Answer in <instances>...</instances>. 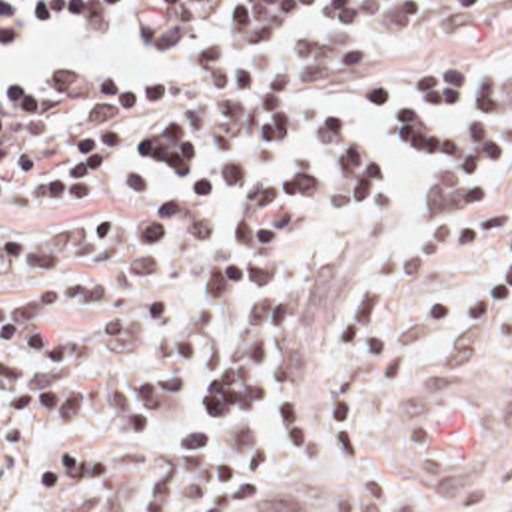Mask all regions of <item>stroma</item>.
Masks as SVG:
<instances>
[{"label": "stroma", "instance_id": "obj_1", "mask_svg": "<svg viewBox=\"0 0 512 512\" xmlns=\"http://www.w3.org/2000/svg\"><path fill=\"white\" fill-rule=\"evenodd\" d=\"M217 10L219 4L215 6L209 28L203 32H217ZM55 16L71 14L59 12ZM510 18L512 0H416V16L412 22L388 36H369L337 22L333 10V26L327 32L301 38L293 48L307 64V124L319 114H345L373 124L359 110L351 84L365 76H382L408 88L404 76L410 64L432 52H454L462 56L472 72L474 84L504 70H512V46L506 36V22ZM99 30L135 42L161 44L125 16L111 18ZM5 38L7 36H1L0 46ZM167 72L169 70L63 66L43 76H161ZM23 78L35 76L0 78V90ZM378 130L388 144L390 178L375 212L361 224H347L329 234H309L293 240L287 248V263L275 277L269 281L243 283L217 305L207 319L203 355L189 387L171 401L137 467L129 499L111 512H139L141 497L177 429L181 409L203 383L215 353L231 331L241 297L251 287L293 291L309 299V313L293 359L301 379L315 387L323 379L341 305L351 287L371 275L392 291L386 333L400 345V373L392 379L378 377L371 381L359 409L361 451L357 459L343 467L331 463L325 451V435L317 419H307L305 423L303 461L293 459L277 445L273 423L261 419L263 429L271 435V453L265 467L249 483L237 512H512V321L502 315L498 317L488 337V351L482 363L470 371L452 367L444 351V323L450 309L482 279L500 269L502 250L492 248L414 289L394 281L392 254L402 230L424 212L418 180L420 170L430 166L404 160L394 152L392 138L382 128ZM245 158L253 172L251 190L283 178L295 164V160L285 164H259L249 156ZM486 170L488 194L484 198H504L498 186L504 160L494 158L486 164ZM121 200L125 198L115 196L103 202L69 204L57 210L0 208V236L13 234L39 218H103L113 224ZM241 200L243 198L211 202L195 210L185 226L201 214L229 218ZM45 279L111 281L109 293L101 305L55 313L59 325L79 333L89 347L99 349L115 313L141 289H155L165 311L175 307L177 252L159 267L101 271L79 263L19 275L0 285V297ZM418 371L470 373L502 389L506 397V455L490 473L446 475L420 461L406 445L398 417L404 395ZM3 415L5 403L0 395V431ZM51 447L53 437L49 435L37 473L15 512H77L105 495L103 491H91L55 501H37V485Z\"/></svg>", "mask_w": 512, "mask_h": 512}]
</instances>
